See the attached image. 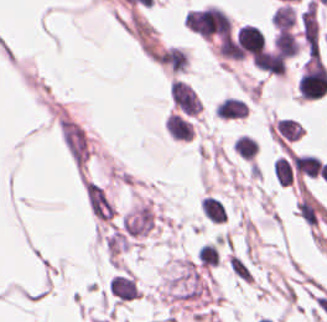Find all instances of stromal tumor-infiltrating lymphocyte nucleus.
Masks as SVG:
<instances>
[{"instance_id": "stromal-tumor-infiltrating-lymphocyte-nucleus-7", "label": "stromal tumor-infiltrating lymphocyte nucleus", "mask_w": 327, "mask_h": 322, "mask_svg": "<svg viewBox=\"0 0 327 322\" xmlns=\"http://www.w3.org/2000/svg\"><path fill=\"white\" fill-rule=\"evenodd\" d=\"M201 209L204 217L214 222L224 221L225 209L218 199L210 196H203L201 201Z\"/></svg>"}, {"instance_id": "stromal-tumor-infiltrating-lymphocyte-nucleus-1", "label": "stromal tumor-infiltrating lymphocyte nucleus", "mask_w": 327, "mask_h": 322, "mask_svg": "<svg viewBox=\"0 0 327 322\" xmlns=\"http://www.w3.org/2000/svg\"><path fill=\"white\" fill-rule=\"evenodd\" d=\"M213 110L217 117L228 120L243 117L248 111L245 102L233 96L221 98Z\"/></svg>"}, {"instance_id": "stromal-tumor-infiltrating-lymphocyte-nucleus-6", "label": "stromal tumor-infiltrating lymphocyte nucleus", "mask_w": 327, "mask_h": 322, "mask_svg": "<svg viewBox=\"0 0 327 322\" xmlns=\"http://www.w3.org/2000/svg\"><path fill=\"white\" fill-rule=\"evenodd\" d=\"M273 174L280 186H290L292 177L291 162L285 155L275 158Z\"/></svg>"}, {"instance_id": "stromal-tumor-infiltrating-lymphocyte-nucleus-2", "label": "stromal tumor-infiltrating lymphocyte nucleus", "mask_w": 327, "mask_h": 322, "mask_svg": "<svg viewBox=\"0 0 327 322\" xmlns=\"http://www.w3.org/2000/svg\"><path fill=\"white\" fill-rule=\"evenodd\" d=\"M293 168L304 176H317L320 168V159L311 154H291L290 156Z\"/></svg>"}, {"instance_id": "stromal-tumor-infiltrating-lymphocyte-nucleus-3", "label": "stromal tumor-infiltrating lymphocyte nucleus", "mask_w": 327, "mask_h": 322, "mask_svg": "<svg viewBox=\"0 0 327 322\" xmlns=\"http://www.w3.org/2000/svg\"><path fill=\"white\" fill-rule=\"evenodd\" d=\"M295 22V10L291 4H283L276 8L272 17L271 24L279 30H291Z\"/></svg>"}, {"instance_id": "stromal-tumor-infiltrating-lymphocyte-nucleus-4", "label": "stromal tumor-infiltrating lymphocyte nucleus", "mask_w": 327, "mask_h": 322, "mask_svg": "<svg viewBox=\"0 0 327 322\" xmlns=\"http://www.w3.org/2000/svg\"><path fill=\"white\" fill-rule=\"evenodd\" d=\"M273 44L281 55H295L298 47V42L290 31L278 30L273 39Z\"/></svg>"}, {"instance_id": "stromal-tumor-infiltrating-lymphocyte-nucleus-5", "label": "stromal tumor-infiltrating lymphocyte nucleus", "mask_w": 327, "mask_h": 322, "mask_svg": "<svg viewBox=\"0 0 327 322\" xmlns=\"http://www.w3.org/2000/svg\"><path fill=\"white\" fill-rule=\"evenodd\" d=\"M232 151L239 157L253 159L258 151V144L251 137L241 135L232 143Z\"/></svg>"}]
</instances>
